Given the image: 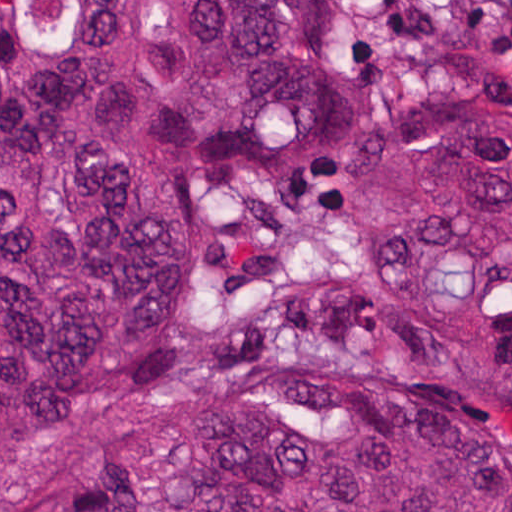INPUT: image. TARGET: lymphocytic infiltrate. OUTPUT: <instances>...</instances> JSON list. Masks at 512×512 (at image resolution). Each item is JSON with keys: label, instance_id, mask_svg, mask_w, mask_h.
<instances>
[{"label": "lymphocytic infiltrate", "instance_id": "lymphocytic-infiltrate-1", "mask_svg": "<svg viewBox=\"0 0 512 512\" xmlns=\"http://www.w3.org/2000/svg\"><path fill=\"white\" fill-rule=\"evenodd\" d=\"M458 31L468 35H497L512 50V0H462Z\"/></svg>", "mask_w": 512, "mask_h": 512}]
</instances>
